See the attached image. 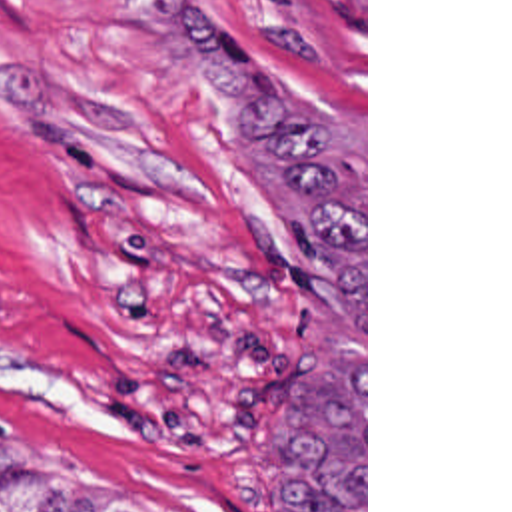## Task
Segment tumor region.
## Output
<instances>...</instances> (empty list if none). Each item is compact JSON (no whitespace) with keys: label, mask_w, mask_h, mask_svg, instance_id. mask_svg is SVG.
<instances>
[{"label":"tumor region","mask_w":512,"mask_h":512,"mask_svg":"<svg viewBox=\"0 0 512 512\" xmlns=\"http://www.w3.org/2000/svg\"><path fill=\"white\" fill-rule=\"evenodd\" d=\"M186 56L240 138L284 188L320 278L364 322V160L274 94L268 70L222 38L200 0H162ZM270 469L292 512H364V368L326 358L298 366L270 428ZM0 512H136L76 475L0 461Z\"/></svg>","instance_id":"obj_1"}]
</instances>
